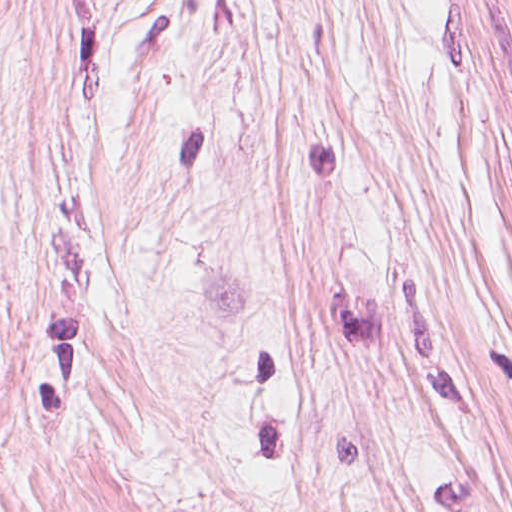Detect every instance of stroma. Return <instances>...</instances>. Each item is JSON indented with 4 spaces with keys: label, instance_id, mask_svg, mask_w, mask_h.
I'll list each match as a JSON object with an SVG mask.
<instances>
[{
    "label": "stroma",
    "instance_id": "obj_1",
    "mask_svg": "<svg viewBox=\"0 0 512 512\" xmlns=\"http://www.w3.org/2000/svg\"><path fill=\"white\" fill-rule=\"evenodd\" d=\"M0 512H512V0H0Z\"/></svg>",
    "mask_w": 512,
    "mask_h": 512
}]
</instances>
